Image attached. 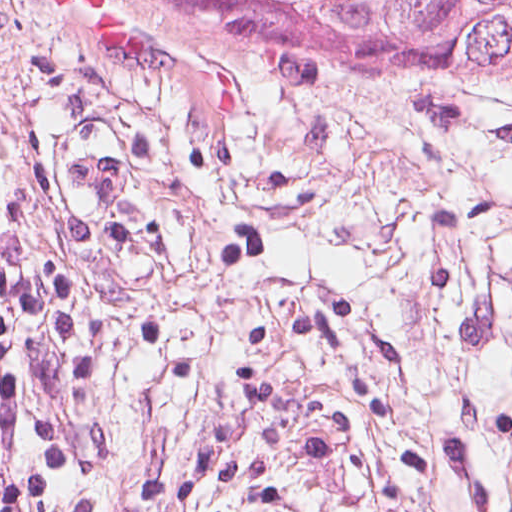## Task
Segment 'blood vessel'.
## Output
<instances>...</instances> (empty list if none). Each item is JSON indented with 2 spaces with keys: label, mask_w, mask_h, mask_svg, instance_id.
Returning <instances> with one entry per match:
<instances>
[{
  "label": "blood vessel",
  "mask_w": 512,
  "mask_h": 512,
  "mask_svg": "<svg viewBox=\"0 0 512 512\" xmlns=\"http://www.w3.org/2000/svg\"><path fill=\"white\" fill-rule=\"evenodd\" d=\"M64 116L44 135L42 174L75 228H98L122 212L138 181V150L112 113Z\"/></svg>",
  "instance_id": "8fb6f2fc"
}]
</instances>
